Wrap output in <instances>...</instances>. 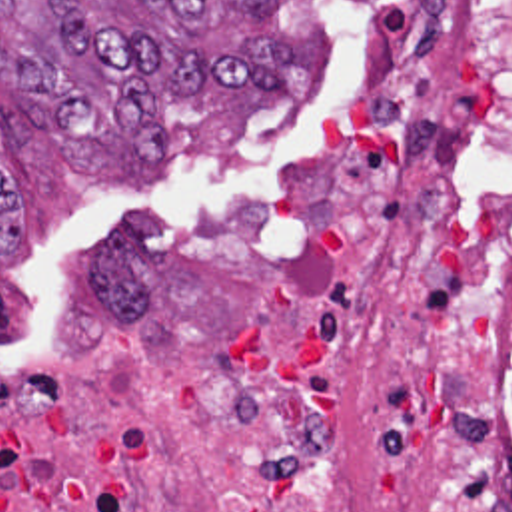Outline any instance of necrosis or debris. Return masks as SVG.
<instances>
[{"instance_id":"1","label":"necrosis or debris","mask_w":512,"mask_h":512,"mask_svg":"<svg viewBox=\"0 0 512 512\" xmlns=\"http://www.w3.org/2000/svg\"><path fill=\"white\" fill-rule=\"evenodd\" d=\"M0 512H512V0H385L315 156L131 222L0 371Z\"/></svg>"}]
</instances>
